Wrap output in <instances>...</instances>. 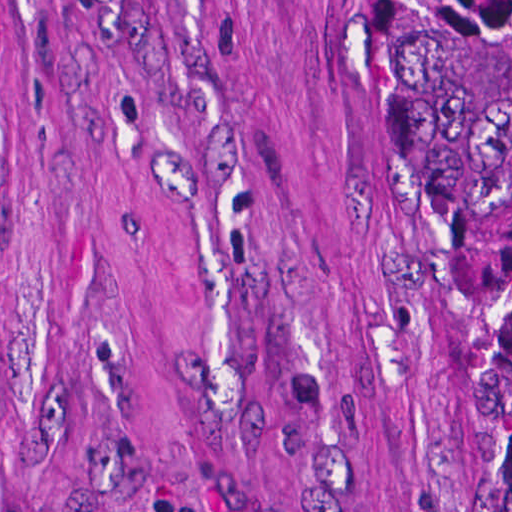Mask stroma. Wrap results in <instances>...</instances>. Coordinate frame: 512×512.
I'll use <instances>...</instances> for the list:
<instances>
[{
	"label": "stroma",
	"instance_id": "35a3bbf8",
	"mask_svg": "<svg viewBox=\"0 0 512 512\" xmlns=\"http://www.w3.org/2000/svg\"><path fill=\"white\" fill-rule=\"evenodd\" d=\"M0 398V512H480L376 0H0Z\"/></svg>",
	"mask_w": 512,
	"mask_h": 512
}]
</instances>
